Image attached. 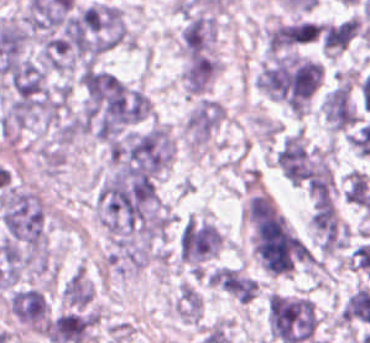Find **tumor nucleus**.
<instances>
[{
	"instance_id": "obj_6",
	"label": "tumor nucleus",
	"mask_w": 370,
	"mask_h": 343,
	"mask_svg": "<svg viewBox=\"0 0 370 343\" xmlns=\"http://www.w3.org/2000/svg\"><path fill=\"white\" fill-rule=\"evenodd\" d=\"M91 6L105 50L125 44L129 35L120 9L105 0H98Z\"/></svg>"
},
{
	"instance_id": "obj_1",
	"label": "tumor nucleus",
	"mask_w": 370,
	"mask_h": 343,
	"mask_svg": "<svg viewBox=\"0 0 370 343\" xmlns=\"http://www.w3.org/2000/svg\"><path fill=\"white\" fill-rule=\"evenodd\" d=\"M222 241L213 223L195 215L182 219L176 236L179 257L192 271H199L218 252Z\"/></svg>"
},
{
	"instance_id": "obj_2",
	"label": "tumor nucleus",
	"mask_w": 370,
	"mask_h": 343,
	"mask_svg": "<svg viewBox=\"0 0 370 343\" xmlns=\"http://www.w3.org/2000/svg\"><path fill=\"white\" fill-rule=\"evenodd\" d=\"M8 308L20 324L42 333L48 304L42 289L19 287L10 294Z\"/></svg>"
},
{
	"instance_id": "obj_4",
	"label": "tumor nucleus",
	"mask_w": 370,
	"mask_h": 343,
	"mask_svg": "<svg viewBox=\"0 0 370 343\" xmlns=\"http://www.w3.org/2000/svg\"><path fill=\"white\" fill-rule=\"evenodd\" d=\"M223 107L213 98L202 97L185 120V132L192 148L203 145L223 121Z\"/></svg>"
},
{
	"instance_id": "obj_8",
	"label": "tumor nucleus",
	"mask_w": 370,
	"mask_h": 343,
	"mask_svg": "<svg viewBox=\"0 0 370 343\" xmlns=\"http://www.w3.org/2000/svg\"><path fill=\"white\" fill-rule=\"evenodd\" d=\"M202 308L201 297L195 287L188 283L179 286L175 301L174 311L184 321H197Z\"/></svg>"
},
{
	"instance_id": "obj_7",
	"label": "tumor nucleus",
	"mask_w": 370,
	"mask_h": 343,
	"mask_svg": "<svg viewBox=\"0 0 370 343\" xmlns=\"http://www.w3.org/2000/svg\"><path fill=\"white\" fill-rule=\"evenodd\" d=\"M61 294L68 305H88L92 300L93 287L84 272L77 267L63 283Z\"/></svg>"
},
{
	"instance_id": "obj_3",
	"label": "tumor nucleus",
	"mask_w": 370,
	"mask_h": 343,
	"mask_svg": "<svg viewBox=\"0 0 370 343\" xmlns=\"http://www.w3.org/2000/svg\"><path fill=\"white\" fill-rule=\"evenodd\" d=\"M216 23L211 15L191 13L184 17L181 45L186 56L213 54Z\"/></svg>"
},
{
	"instance_id": "obj_5",
	"label": "tumor nucleus",
	"mask_w": 370,
	"mask_h": 343,
	"mask_svg": "<svg viewBox=\"0 0 370 343\" xmlns=\"http://www.w3.org/2000/svg\"><path fill=\"white\" fill-rule=\"evenodd\" d=\"M218 72V59L209 53H189L182 83L189 96H203Z\"/></svg>"
}]
</instances>
